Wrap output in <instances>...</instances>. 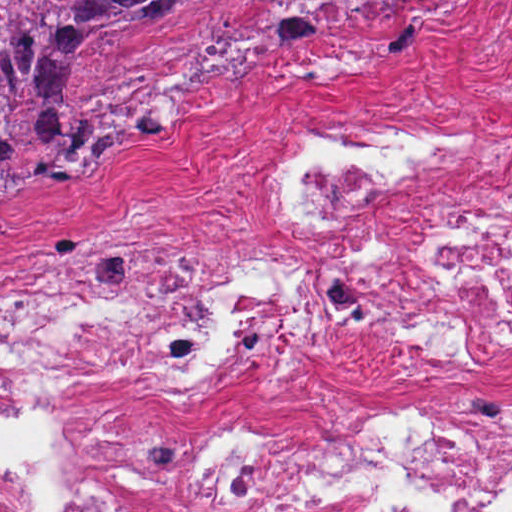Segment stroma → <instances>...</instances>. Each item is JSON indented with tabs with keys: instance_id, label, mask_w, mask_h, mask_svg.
Here are the masks:
<instances>
[{
	"instance_id": "obj_1",
	"label": "stroma",
	"mask_w": 512,
	"mask_h": 512,
	"mask_svg": "<svg viewBox=\"0 0 512 512\" xmlns=\"http://www.w3.org/2000/svg\"><path fill=\"white\" fill-rule=\"evenodd\" d=\"M83 102L178 126L120 144L75 184L0 198V273L70 258L127 217L192 264L298 267L309 255L271 187L304 131L377 123L492 148L486 167L433 178L360 211L354 241L403 257L512 205V0H225L146 36L74 55ZM512 390V351L428 359L367 308L292 319L184 388H77L0 362V464L53 487L30 424L290 427L403 417L444 398Z\"/></svg>"
}]
</instances>
